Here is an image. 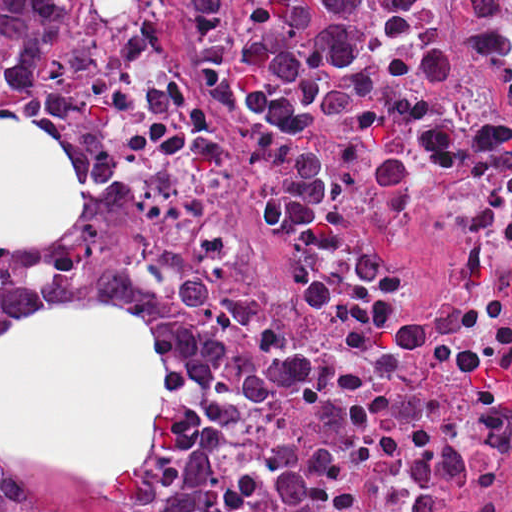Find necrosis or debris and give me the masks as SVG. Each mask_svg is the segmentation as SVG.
I'll use <instances>...</instances> for the list:
<instances>
[{
	"instance_id": "4bbe7bcc",
	"label": "necrosis or debris",
	"mask_w": 512,
	"mask_h": 512,
	"mask_svg": "<svg viewBox=\"0 0 512 512\" xmlns=\"http://www.w3.org/2000/svg\"><path fill=\"white\" fill-rule=\"evenodd\" d=\"M430 4L440 69L311 124L313 240L267 233L288 145L192 70L196 0H102L89 27L104 165L216 325L203 512H512V0Z\"/></svg>"
}]
</instances>
